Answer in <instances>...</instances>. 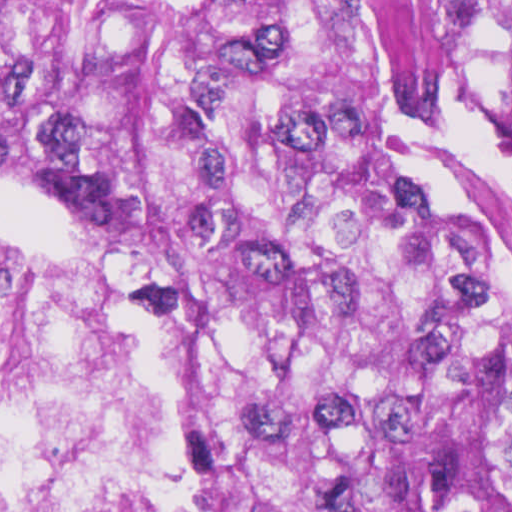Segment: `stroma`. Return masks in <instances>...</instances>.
Segmentation results:
<instances>
[{
	"mask_svg": "<svg viewBox=\"0 0 512 512\" xmlns=\"http://www.w3.org/2000/svg\"><path fill=\"white\" fill-rule=\"evenodd\" d=\"M0 190H13L27 196L53 214L66 232L88 245L111 269L132 298L157 313L182 340V313L142 293L126 271L101 243L88 224L71 203L53 191L27 177L0 137ZM37 244L26 238H8ZM40 245V244H37ZM188 357V348H187ZM176 397L180 420H182L186 441L200 464L208 482L214 512H228L223 496L200 459L182 392V379L172 392ZM162 395V396H171Z\"/></svg>",
	"mask_w": 512,
	"mask_h": 512,
	"instance_id": "1",
	"label": "stroma"
}]
</instances>
